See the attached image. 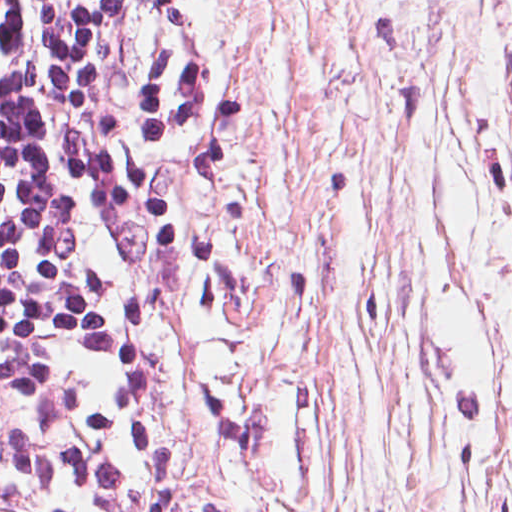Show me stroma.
<instances>
[{
	"label": "stroma",
	"instance_id": "1",
	"mask_svg": "<svg viewBox=\"0 0 512 512\" xmlns=\"http://www.w3.org/2000/svg\"><path fill=\"white\" fill-rule=\"evenodd\" d=\"M145 1L152 512H512V0Z\"/></svg>",
	"mask_w": 512,
	"mask_h": 512
}]
</instances>
